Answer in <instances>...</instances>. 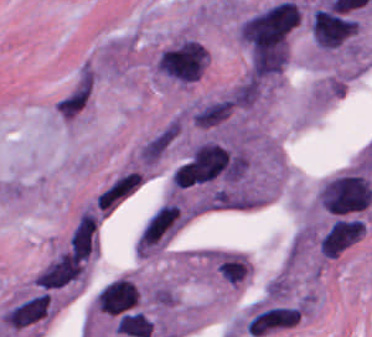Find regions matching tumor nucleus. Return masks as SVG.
Returning <instances> with one entry per match:
<instances>
[{
    "instance_id": "1",
    "label": "tumor nucleus",
    "mask_w": 372,
    "mask_h": 337,
    "mask_svg": "<svg viewBox=\"0 0 372 337\" xmlns=\"http://www.w3.org/2000/svg\"><path fill=\"white\" fill-rule=\"evenodd\" d=\"M235 175V152L207 139L194 145L177 165L171 185L180 189Z\"/></svg>"
},
{
    "instance_id": "3",
    "label": "tumor nucleus",
    "mask_w": 372,
    "mask_h": 337,
    "mask_svg": "<svg viewBox=\"0 0 372 337\" xmlns=\"http://www.w3.org/2000/svg\"><path fill=\"white\" fill-rule=\"evenodd\" d=\"M154 66L172 82L189 83L205 72V46L194 36H181L159 51Z\"/></svg>"
},
{
    "instance_id": "4",
    "label": "tumor nucleus",
    "mask_w": 372,
    "mask_h": 337,
    "mask_svg": "<svg viewBox=\"0 0 372 337\" xmlns=\"http://www.w3.org/2000/svg\"><path fill=\"white\" fill-rule=\"evenodd\" d=\"M358 22L343 12L316 6L310 15L312 38L320 48L341 44L357 31Z\"/></svg>"
},
{
    "instance_id": "7",
    "label": "tumor nucleus",
    "mask_w": 372,
    "mask_h": 337,
    "mask_svg": "<svg viewBox=\"0 0 372 337\" xmlns=\"http://www.w3.org/2000/svg\"><path fill=\"white\" fill-rule=\"evenodd\" d=\"M301 309L296 306H276L256 313L246 329L251 335H264L295 325L300 319Z\"/></svg>"
},
{
    "instance_id": "2",
    "label": "tumor nucleus",
    "mask_w": 372,
    "mask_h": 337,
    "mask_svg": "<svg viewBox=\"0 0 372 337\" xmlns=\"http://www.w3.org/2000/svg\"><path fill=\"white\" fill-rule=\"evenodd\" d=\"M184 227V210L178 198L168 197L153 207L139 227L132 250L138 258L157 257Z\"/></svg>"
},
{
    "instance_id": "9",
    "label": "tumor nucleus",
    "mask_w": 372,
    "mask_h": 337,
    "mask_svg": "<svg viewBox=\"0 0 372 337\" xmlns=\"http://www.w3.org/2000/svg\"><path fill=\"white\" fill-rule=\"evenodd\" d=\"M49 296L39 293L6 310L0 322L10 327H23L43 319L47 315Z\"/></svg>"
},
{
    "instance_id": "5",
    "label": "tumor nucleus",
    "mask_w": 372,
    "mask_h": 337,
    "mask_svg": "<svg viewBox=\"0 0 372 337\" xmlns=\"http://www.w3.org/2000/svg\"><path fill=\"white\" fill-rule=\"evenodd\" d=\"M137 175L117 170L92 195L90 206L104 220L136 194Z\"/></svg>"
},
{
    "instance_id": "8",
    "label": "tumor nucleus",
    "mask_w": 372,
    "mask_h": 337,
    "mask_svg": "<svg viewBox=\"0 0 372 337\" xmlns=\"http://www.w3.org/2000/svg\"><path fill=\"white\" fill-rule=\"evenodd\" d=\"M70 250L71 254L86 261L98 254L97 220L88 207L70 236Z\"/></svg>"
},
{
    "instance_id": "6",
    "label": "tumor nucleus",
    "mask_w": 372,
    "mask_h": 337,
    "mask_svg": "<svg viewBox=\"0 0 372 337\" xmlns=\"http://www.w3.org/2000/svg\"><path fill=\"white\" fill-rule=\"evenodd\" d=\"M85 273V261L67 251H60L34 277L38 286L54 288L78 279Z\"/></svg>"
}]
</instances>
